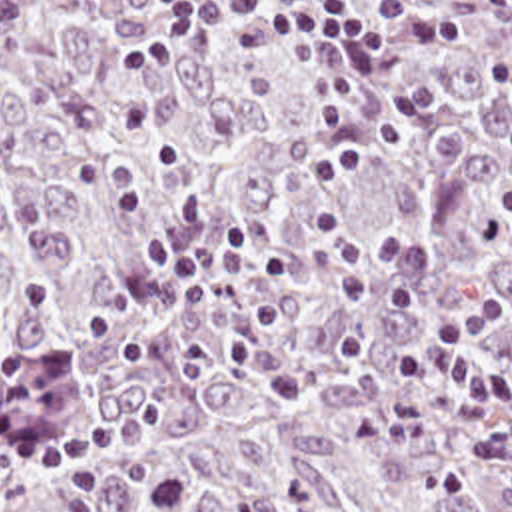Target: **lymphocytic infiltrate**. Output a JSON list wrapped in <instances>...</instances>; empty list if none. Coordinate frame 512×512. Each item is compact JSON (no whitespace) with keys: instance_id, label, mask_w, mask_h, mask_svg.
I'll use <instances>...</instances> for the list:
<instances>
[{"instance_id":"obj_1","label":"lymphocytic infiltrate","mask_w":512,"mask_h":512,"mask_svg":"<svg viewBox=\"0 0 512 512\" xmlns=\"http://www.w3.org/2000/svg\"><path fill=\"white\" fill-rule=\"evenodd\" d=\"M502 24L512 38V0H460ZM156 24L128 42L118 58L124 72H142L180 56L198 36L212 40L224 26L246 22L268 44H282L304 62L314 86V128L324 154L312 160V188L306 212L312 254L318 268L342 290L356 296L374 316L386 344L388 362L404 380H434V394H412L384 402L374 430L394 445H424L436 422L468 414L472 396L510 390V378L482 360L486 338L510 322L498 304L468 320L434 332L420 348L406 350L396 326L416 310V292L394 286L376 296L358 276L352 260V232L342 210V190L368 156L384 154L398 142V130L362 88L360 74L382 82L400 114L418 122L434 106L408 68L412 48L454 38L462 28L422 0H390L384 24L372 26L330 0H158ZM140 256L162 280L240 278L250 266L256 290L246 320L250 332H276L284 324V292L292 278V250L268 240L236 220L224 222L202 244L182 248L162 236H148ZM158 410L156 392H140L108 424L72 430L37 451L45 469H62L96 445L138 441L146 420Z\"/></svg>"}]
</instances>
